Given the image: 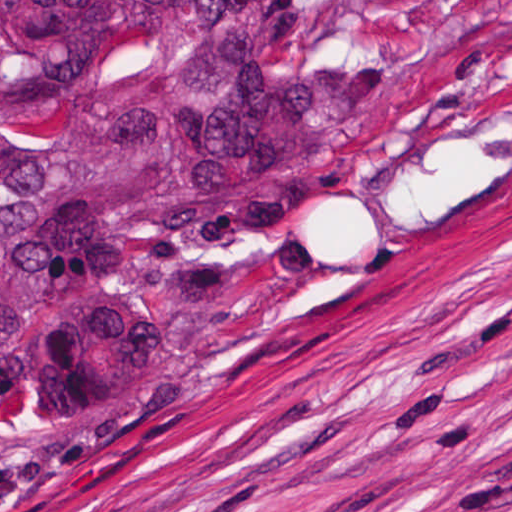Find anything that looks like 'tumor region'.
<instances>
[{"instance_id": "obj_1", "label": "tumor region", "mask_w": 512, "mask_h": 512, "mask_svg": "<svg viewBox=\"0 0 512 512\" xmlns=\"http://www.w3.org/2000/svg\"><path fill=\"white\" fill-rule=\"evenodd\" d=\"M512 164V0H0V426L226 370Z\"/></svg>"}]
</instances>
